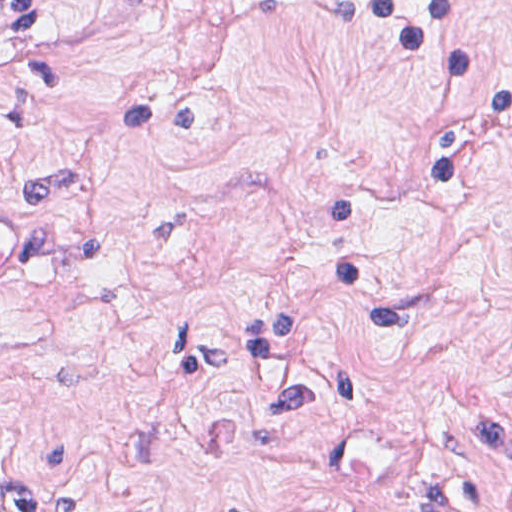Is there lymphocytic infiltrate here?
Wrapping results in <instances>:
<instances>
[{"mask_svg": "<svg viewBox=\"0 0 512 512\" xmlns=\"http://www.w3.org/2000/svg\"><path fill=\"white\" fill-rule=\"evenodd\" d=\"M389 30L441 85L431 155L343 161L315 200V271L324 300L364 331L408 322L398 304L370 299V262L347 231L350 214L410 177H467L512 147V79L486 45L475 0H320ZM59 512H93L73 492ZM0 512H42L30 486L0 485Z\"/></svg>", "mask_w": 512, "mask_h": 512, "instance_id": "1", "label": "lymphocytic infiltrate"}]
</instances>
